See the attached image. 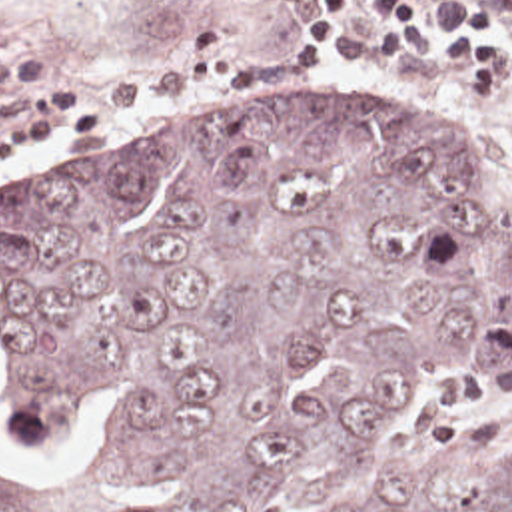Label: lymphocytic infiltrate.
<instances>
[{
  "mask_svg": "<svg viewBox=\"0 0 512 512\" xmlns=\"http://www.w3.org/2000/svg\"><path fill=\"white\" fill-rule=\"evenodd\" d=\"M291 17L273 55L325 73L337 55L376 61L412 53L450 67L472 91H512V21L480 0L368 1V29L356 0H271ZM111 129V109L75 87L0 89V160H19L37 137L75 139Z\"/></svg>",
  "mask_w": 512,
  "mask_h": 512,
  "instance_id": "obj_1",
  "label": "lymphocytic infiltrate"
}]
</instances>
